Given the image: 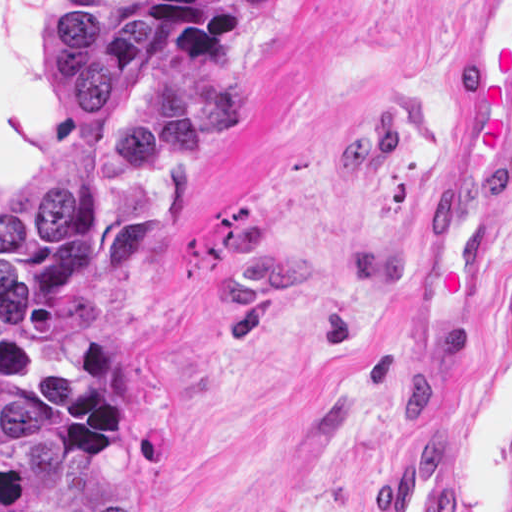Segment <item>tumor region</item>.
Masks as SVG:
<instances>
[{"label":"tumor region","instance_id":"tumor-region-1","mask_svg":"<svg viewBox=\"0 0 512 512\" xmlns=\"http://www.w3.org/2000/svg\"><path fill=\"white\" fill-rule=\"evenodd\" d=\"M53 1L75 130L0 201V512H135L142 417L94 332L153 269L149 175L218 159L239 109L194 81L135 80L160 38L142 0Z\"/></svg>","mask_w":512,"mask_h":512}]
</instances>
